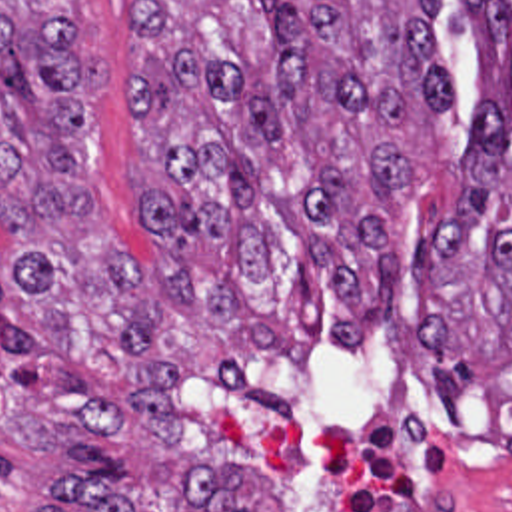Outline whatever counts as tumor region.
Segmentation results:
<instances>
[{
  "instance_id": "e687c5a6",
  "label": "tumor region",
  "mask_w": 512,
  "mask_h": 512,
  "mask_svg": "<svg viewBox=\"0 0 512 512\" xmlns=\"http://www.w3.org/2000/svg\"><path fill=\"white\" fill-rule=\"evenodd\" d=\"M71 0H0V358L103 436L173 447L183 372L155 364L153 288L225 342L301 366L359 358L389 330L405 258L389 212L409 196L413 116L455 104L433 18L443 0H139L131 122L159 150L139 214L155 262L125 252L79 166L97 72ZM479 44L465 198L417 254L423 390L512 408V0H467ZM59 481L79 512L133 511L109 477ZM243 473L195 461L209 512H253ZM43 512H63L55 507Z\"/></svg>"
}]
</instances>
